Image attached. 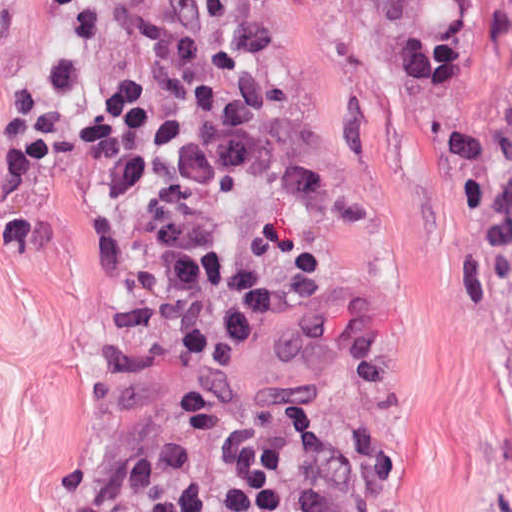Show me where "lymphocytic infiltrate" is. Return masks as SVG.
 I'll return each mask as SVG.
<instances>
[{
	"label": "lymphocytic infiltrate",
	"instance_id": "lymphocytic-infiltrate-1",
	"mask_svg": "<svg viewBox=\"0 0 512 512\" xmlns=\"http://www.w3.org/2000/svg\"><path fill=\"white\" fill-rule=\"evenodd\" d=\"M41 83L58 150L99 214L131 190L216 178L267 148L286 68L263 0H53ZM100 512H401L362 461L277 408L231 443L119 485Z\"/></svg>",
	"mask_w": 512,
	"mask_h": 512
}]
</instances>
